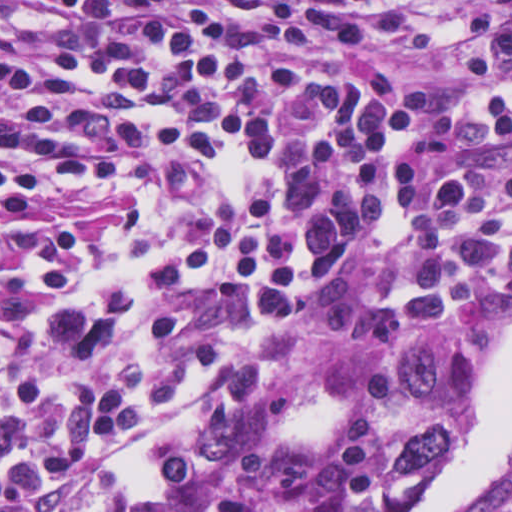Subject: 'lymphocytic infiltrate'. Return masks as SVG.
I'll return each mask as SVG.
<instances>
[{"label":"lymphocytic infiltrate","mask_w":512,"mask_h":512,"mask_svg":"<svg viewBox=\"0 0 512 512\" xmlns=\"http://www.w3.org/2000/svg\"><path fill=\"white\" fill-rule=\"evenodd\" d=\"M0 4L64 32L0 44V318L27 311L9 267L50 292L88 272L92 234L34 227L55 195L122 157L184 213L220 162L247 174L215 224L0 334V512H410L376 489L385 370L291 454L255 414L310 326L388 349L512 297V6Z\"/></svg>","instance_id":"obj_1"}]
</instances>
